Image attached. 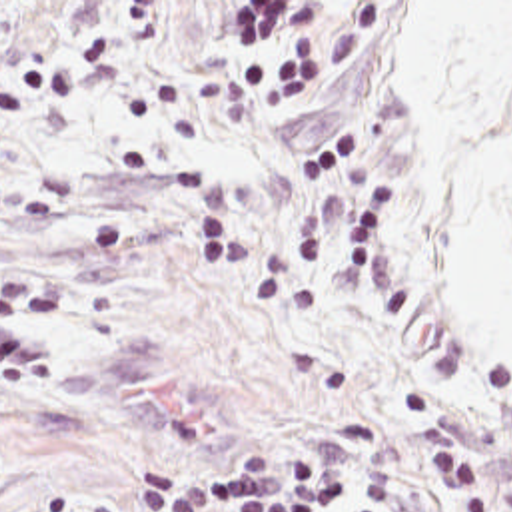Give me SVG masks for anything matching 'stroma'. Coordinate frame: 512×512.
<instances>
[{"label":"stroma","mask_w":512,"mask_h":512,"mask_svg":"<svg viewBox=\"0 0 512 512\" xmlns=\"http://www.w3.org/2000/svg\"><path fill=\"white\" fill-rule=\"evenodd\" d=\"M2 270L52 371L0 377V512L316 445L352 512L298 0L2 30Z\"/></svg>","instance_id":"stroma-1"}]
</instances>
